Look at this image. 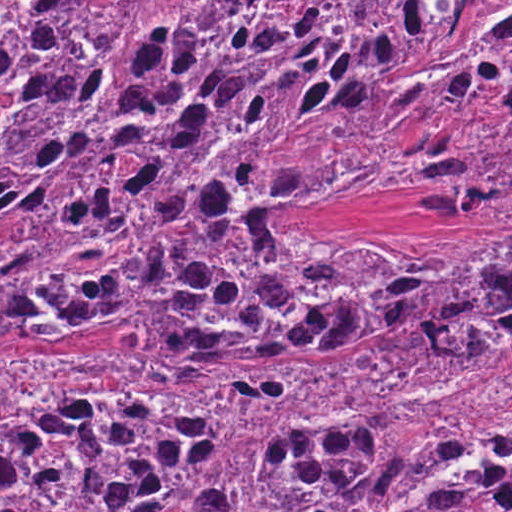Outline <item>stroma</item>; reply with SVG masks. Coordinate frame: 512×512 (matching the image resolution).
<instances>
[{
    "instance_id": "stroma-1",
    "label": "stroma",
    "mask_w": 512,
    "mask_h": 512,
    "mask_svg": "<svg viewBox=\"0 0 512 512\" xmlns=\"http://www.w3.org/2000/svg\"><path fill=\"white\" fill-rule=\"evenodd\" d=\"M0 1H512V0H0ZM473 20V19H472ZM471 20V21H472ZM470 21V22H471ZM437 195L431 193H363L347 201L315 203L290 215H220L197 217L177 232L191 226L216 221H245L263 230H276L311 244L358 238L393 248H433L462 237H494L493 220H450L424 217L415 211ZM169 233V234H171ZM166 234V235H169ZM164 235V236H166ZM163 236V237H164ZM158 238L116 239L44 260L35 270H12L7 277L40 275L67 270H83L122 263ZM125 337L104 339H0V344H82L108 347ZM468 345H477L460 340ZM387 347L386 339L357 337L331 339L297 347H282L306 358H343L367 350Z\"/></svg>"
}]
</instances>
